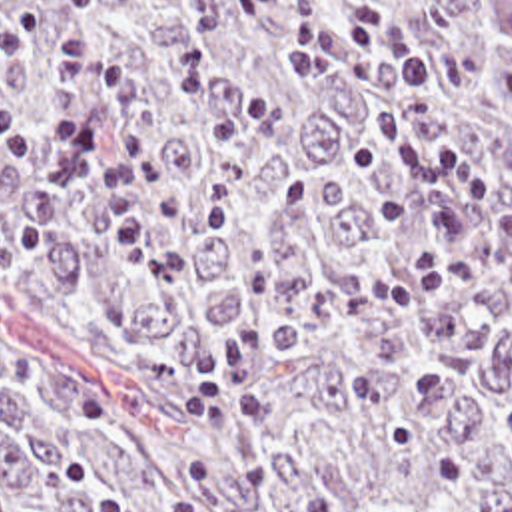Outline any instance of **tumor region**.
<instances>
[{
	"mask_svg": "<svg viewBox=\"0 0 512 512\" xmlns=\"http://www.w3.org/2000/svg\"><path fill=\"white\" fill-rule=\"evenodd\" d=\"M390 15L438 65L432 139L512 199V0H0V99L49 127L84 27L148 81L162 263L98 249L86 189L116 97L86 87L56 193L0 149V512H512V295L402 183L386 87L340 19Z\"/></svg>",
	"mask_w": 512,
	"mask_h": 512,
	"instance_id": "tumor-region-1",
	"label": "tumor region"
}]
</instances>
